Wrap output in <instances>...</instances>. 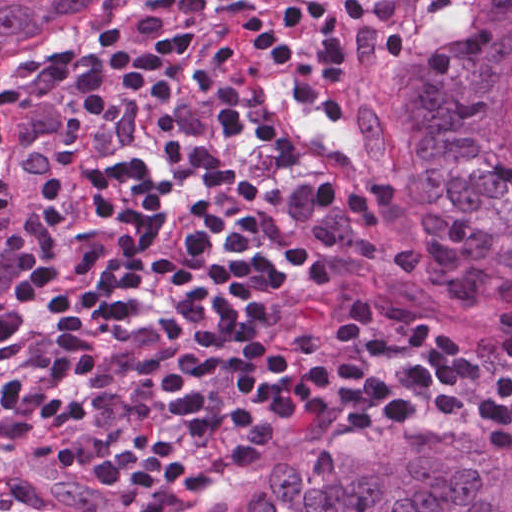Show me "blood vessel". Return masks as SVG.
Wrapping results in <instances>:
<instances>
[{"label": "blood vessel", "instance_id": "obj_1", "mask_svg": "<svg viewBox=\"0 0 512 512\" xmlns=\"http://www.w3.org/2000/svg\"><path fill=\"white\" fill-rule=\"evenodd\" d=\"M286 47L254 60L232 86L234 118L283 168L366 188L379 176L373 118L308 54ZM19 257L20 229L9 220L0 225V308Z\"/></svg>", "mask_w": 512, "mask_h": 512}]
</instances>
